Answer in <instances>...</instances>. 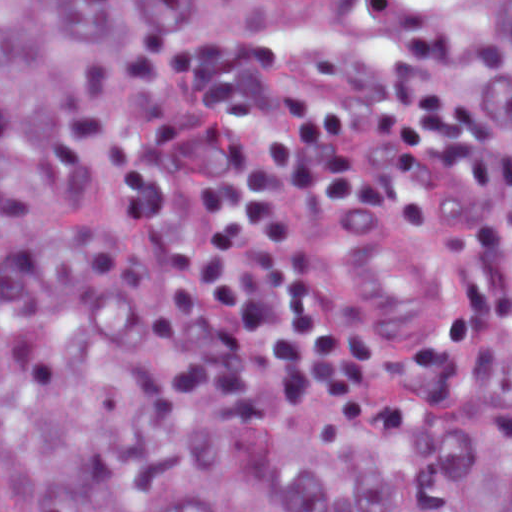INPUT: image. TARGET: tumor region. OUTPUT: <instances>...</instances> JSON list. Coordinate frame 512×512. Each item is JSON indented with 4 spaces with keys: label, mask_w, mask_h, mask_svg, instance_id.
Returning a JSON list of instances; mask_svg holds the SVG:
<instances>
[{
    "label": "tumor region",
    "mask_w": 512,
    "mask_h": 512,
    "mask_svg": "<svg viewBox=\"0 0 512 512\" xmlns=\"http://www.w3.org/2000/svg\"><path fill=\"white\" fill-rule=\"evenodd\" d=\"M294 54L432 78L505 235L470 379L329 447L201 377L111 252L126 106ZM0 512H512V0H0Z\"/></svg>",
    "instance_id": "1"
}]
</instances>
